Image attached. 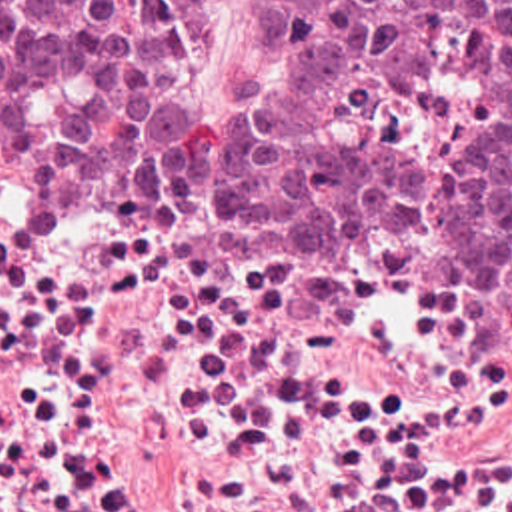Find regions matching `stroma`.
Here are the masks:
<instances>
[{"mask_svg": "<svg viewBox=\"0 0 512 512\" xmlns=\"http://www.w3.org/2000/svg\"><path fill=\"white\" fill-rule=\"evenodd\" d=\"M278 68L210 0L192 98ZM0 512H512V316L436 252L346 260V428H0Z\"/></svg>", "mask_w": 512, "mask_h": 512, "instance_id": "obj_1", "label": "stroma"}]
</instances>
